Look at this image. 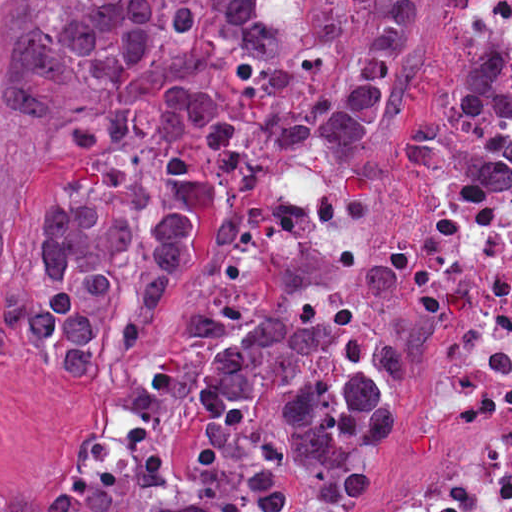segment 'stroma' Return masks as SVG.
I'll return each mask as SVG.
<instances>
[{
  "label": "stroma",
  "instance_id": "obj_1",
  "mask_svg": "<svg viewBox=\"0 0 512 512\" xmlns=\"http://www.w3.org/2000/svg\"><path fill=\"white\" fill-rule=\"evenodd\" d=\"M427 17L402 111L376 141L344 152L280 148L269 156L256 221L233 242L202 251L190 290L223 320L287 314L301 323L351 320L344 350L384 371L399 396L397 431L375 449L369 494L334 503L293 471L300 512H362L387 495L425 488L475 448V408L447 377L434 331L402 291L388 244L392 226L447 191L511 203L508 191L461 180H404L398 128L429 111L456 82L469 41L504 46L512 81V34L468 15L457 0H417ZM457 57V58H456ZM456 58V59H455ZM90 156L0 103V215L32 232L80 188ZM171 322L144 345L89 378L74 376L30 345L0 335V484L50 470L101 423H132L129 391L155 370Z\"/></svg>",
  "mask_w": 512,
  "mask_h": 512
}]
</instances>
